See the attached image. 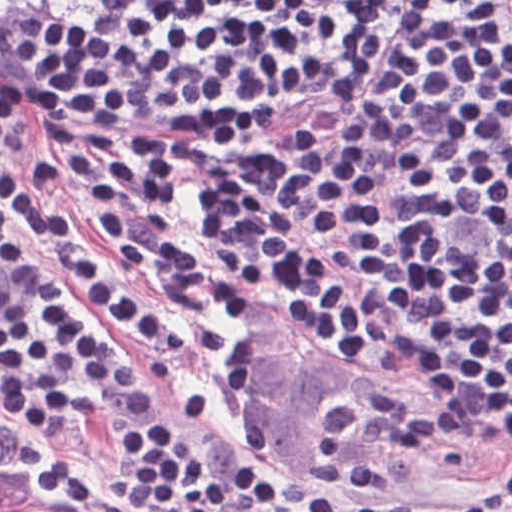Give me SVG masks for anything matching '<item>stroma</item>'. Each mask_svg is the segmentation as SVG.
I'll use <instances>...</instances> for the list:
<instances>
[{
	"mask_svg": "<svg viewBox=\"0 0 512 512\" xmlns=\"http://www.w3.org/2000/svg\"><path fill=\"white\" fill-rule=\"evenodd\" d=\"M102 0H69L0 33V81L10 102L15 141L68 169L65 154L30 136L17 111V92L32 71V33L51 15ZM431 0H376L366 19L316 72L264 92L273 105L266 142L223 163H201L178 185L185 245L193 212L205 193L214 212L252 235L317 266L336 286L388 322L410 331L403 295L310 198L283 175L324 146L337 125L393 63ZM26 261L50 268L82 247L115 263L141 299L181 328L178 350L128 338L100 321L116 348L150 356L170 368L155 378L159 410L183 390L207 395L195 420L178 428L180 450L220 464L253 463L240 445L237 394L266 469L293 471L341 490L374 488L383 498L407 494L495 502L474 512H512V424L457 410L322 341L279 311L374 358V349L340 339L285 306L229 289L208 318L172 308L144 271L97 241L50 243L11 233ZM455 398V397H454ZM142 429L108 421L72 422L65 439H43L0 425V447L29 466L51 489L87 512H145L119 493V434Z\"/></svg>",
	"mask_w": 512,
	"mask_h": 512,
	"instance_id": "obj_1",
	"label": "stroma"
}]
</instances>
